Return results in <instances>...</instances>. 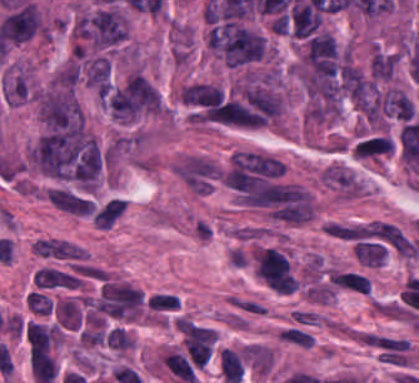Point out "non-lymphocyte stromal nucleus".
I'll return each instance as SVG.
<instances>
[{
	"label": "non-lymphocyte stromal nucleus",
	"instance_id": "obj_1",
	"mask_svg": "<svg viewBox=\"0 0 419 383\" xmlns=\"http://www.w3.org/2000/svg\"><path fill=\"white\" fill-rule=\"evenodd\" d=\"M257 277L276 293H293L296 275L282 251L263 247L254 263Z\"/></svg>",
	"mask_w": 419,
	"mask_h": 383
},
{
	"label": "non-lymphocyte stromal nucleus",
	"instance_id": "obj_2",
	"mask_svg": "<svg viewBox=\"0 0 419 383\" xmlns=\"http://www.w3.org/2000/svg\"><path fill=\"white\" fill-rule=\"evenodd\" d=\"M48 199L59 209L80 215H90V200L63 188H49Z\"/></svg>",
	"mask_w": 419,
	"mask_h": 383
},
{
	"label": "non-lymphocyte stromal nucleus",
	"instance_id": "obj_3",
	"mask_svg": "<svg viewBox=\"0 0 419 383\" xmlns=\"http://www.w3.org/2000/svg\"><path fill=\"white\" fill-rule=\"evenodd\" d=\"M124 201L118 198H110L92 217V221L98 228H109L122 214Z\"/></svg>",
	"mask_w": 419,
	"mask_h": 383
},
{
	"label": "non-lymphocyte stromal nucleus",
	"instance_id": "obj_4",
	"mask_svg": "<svg viewBox=\"0 0 419 383\" xmlns=\"http://www.w3.org/2000/svg\"><path fill=\"white\" fill-rule=\"evenodd\" d=\"M228 303L249 315H264L265 306L249 296L229 295Z\"/></svg>",
	"mask_w": 419,
	"mask_h": 383
},
{
	"label": "non-lymphocyte stromal nucleus",
	"instance_id": "obj_5",
	"mask_svg": "<svg viewBox=\"0 0 419 383\" xmlns=\"http://www.w3.org/2000/svg\"><path fill=\"white\" fill-rule=\"evenodd\" d=\"M77 280H79V276L75 271L54 267L44 290L60 288Z\"/></svg>",
	"mask_w": 419,
	"mask_h": 383
},
{
	"label": "non-lymphocyte stromal nucleus",
	"instance_id": "obj_6",
	"mask_svg": "<svg viewBox=\"0 0 419 383\" xmlns=\"http://www.w3.org/2000/svg\"><path fill=\"white\" fill-rule=\"evenodd\" d=\"M278 335L281 340L300 346H311L313 342V336L311 334L292 327L282 330Z\"/></svg>",
	"mask_w": 419,
	"mask_h": 383
}]
</instances>
